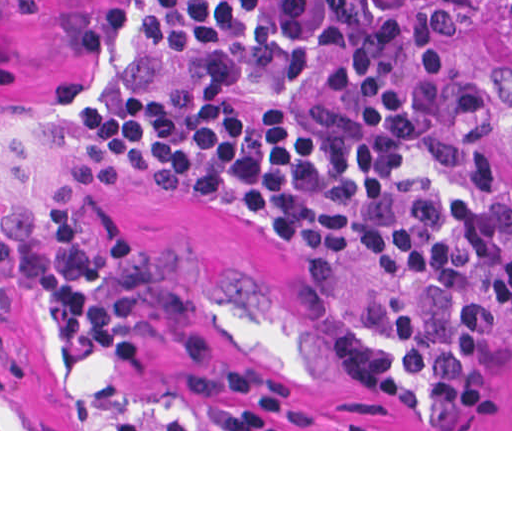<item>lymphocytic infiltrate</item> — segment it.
<instances>
[{"label":"lymphocytic infiltrate","instance_id":"1","mask_svg":"<svg viewBox=\"0 0 512 512\" xmlns=\"http://www.w3.org/2000/svg\"><path fill=\"white\" fill-rule=\"evenodd\" d=\"M476 69L420 0H150L81 138L115 179L230 199L318 294L352 262L406 283L428 402L451 429L512 324L495 107ZM38 294L68 354L140 369L155 340L219 358L194 294L147 246L91 243L67 207L46 232L23 204L0 214V388L25 366L4 329Z\"/></svg>","mask_w":512,"mask_h":512}]
</instances>
